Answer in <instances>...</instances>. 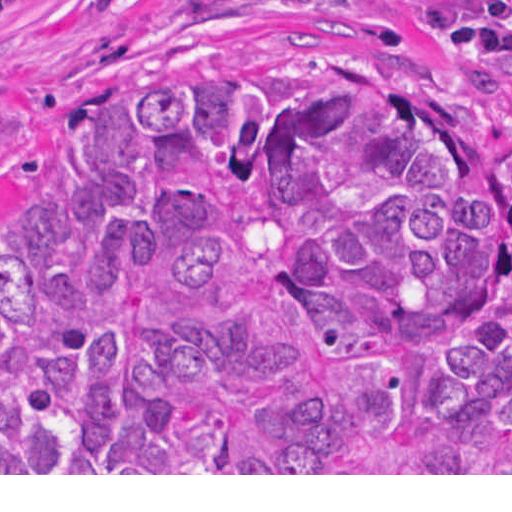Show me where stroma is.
<instances>
[{
    "label": "stroma",
    "instance_id": "obj_1",
    "mask_svg": "<svg viewBox=\"0 0 512 512\" xmlns=\"http://www.w3.org/2000/svg\"><path fill=\"white\" fill-rule=\"evenodd\" d=\"M416 0H40L0 20V263L29 250L37 206L72 179L102 97L204 64L310 57L512 127ZM473 13L488 0H469ZM0 475H512V473H0Z\"/></svg>",
    "mask_w": 512,
    "mask_h": 512
}]
</instances>
